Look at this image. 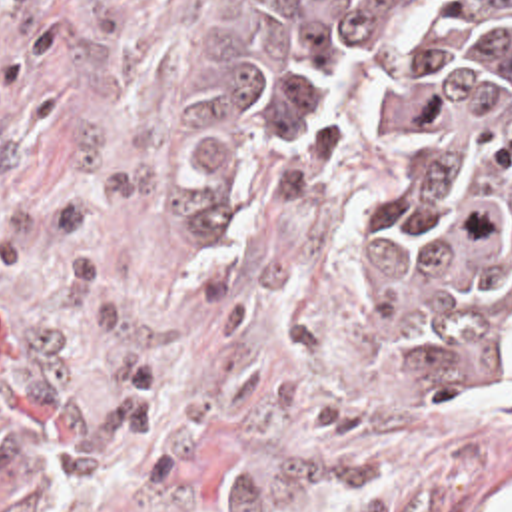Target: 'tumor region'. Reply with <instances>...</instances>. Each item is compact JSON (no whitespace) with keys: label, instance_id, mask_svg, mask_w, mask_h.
I'll return each instance as SVG.
<instances>
[{"label":"tumor region","instance_id":"1","mask_svg":"<svg viewBox=\"0 0 512 512\" xmlns=\"http://www.w3.org/2000/svg\"><path fill=\"white\" fill-rule=\"evenodd\" d=\"M214 157H360L390 351L450 399L512 391V0H258Z\"/></svg>","mask_w":512,"mask_h":512}]
</instances>
